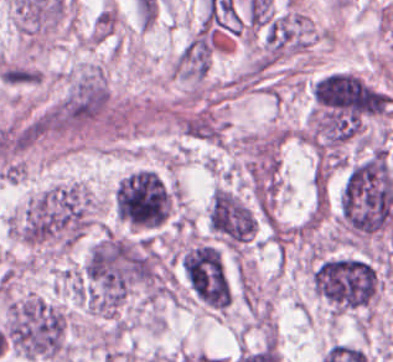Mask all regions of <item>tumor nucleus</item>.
<instances>
[{"instance_id":"2f306a5c","label":"tumor nucleus","mask_w":393,"mask_h":362,"mask_svg":"<svg viewBox=\"0 0 393 362\" xmlns=\"http://www.w3.org/2000/svg\"><path fill=\"white\" fill-rule=\"evenodd\" d=\"M94 196L79 179L32 192L3 218L6 237L36 262H55L78 244L93 223Z\"/></svg>"},{"instance_id":"8643909e","label":"tumor nucleus","mask_w":393,"mask_h":362,"mask_svg":"<svg viewBox=\"0 0 393 362\" xmlns=\"http://www.w3.org/2000/svg\"><path fill=\"white\" fill-rule=\"evenodd\" d=\"M309 289L329 322H367L379 300L378 267L361 257L329 255L308 270Z\"/></svg>"},{"instance_id":"5ab6c2c4","label":"tumor nucleus","mask_w":393,"mask_h":362,"mask_svg":"<svg viewBox=\"0 0 393 362\" xmlns=\"http://www.w3.org/2000/svg\"><path fill=\"white\" fill-rule=\"evenodd\" d=\"M0 330L8 349L32 360L69 362L66 307L35 293H15L2 308Z\"/></svg>"},{"instance_id":"2cbd58db","label":"tumor nucleus","mask_w":393,"mask_h":362,"mask_svg":"<svg viewBox=\"0 0 393 362\" xmlns=\"http://www.w3.org/2000/svg\"><path fill=\"white\" fill-rule=\"evenodd\" d=\"M109 209L128 230L154 231L166 219V187L151 169H132L113 185Z\"/></svg>"},{"instance_id":"3d1891a8","label":"tumor nucleus","mask_w":393,"mask_h":362,"mask_svg":"<svg viewBox=\"0 0 393 362\" xmlns=\"http://www.w3.org/2000/svg\"><path fill=\"white\" fill-rule=\"evenodd\" d=\"M176 264L186 289L200 304L220 313L228 307L230 283L218 245L189 240Z\"/></svg>"},{"instance_id":"2083b535","label":"tumor nucleus","mask_w":393,"mask_h":362,"mask_svg":"<svg viewBox=\"0 0 393 362\" xmlns=\"http://www.w3.org/2000/svg\"><path fill=\"white\" fill-rule=\"evenodd\" d=\"M209 235L217 245L248 246L258 232V218L253 205L237 190L217 184L205 208Z\"/></svg>"}]
</instances>
